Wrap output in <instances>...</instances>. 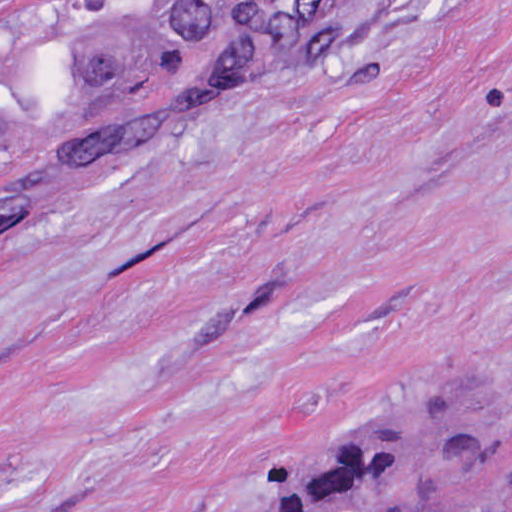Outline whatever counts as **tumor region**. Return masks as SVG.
I'll return each instance as SVG.
<instances>
[{
  "instance_id": "tumor-region-1",
  "label": "tumor region",
  "mask_w": 512,
  "mask_h": 512,
  "mask_svg": "<svg viewBox=\"0 0 512 512\" xmlns=\"http://www.w3.org/2000/svg\"><path fill=\"white\" fill-rule=\"evenodd\" d=\"M298 5L0 1V172L23 169L0 184V228L229 71ZM499 447L495 386L442 383L340 437L313 422L205 504L247 480L249 512H441Z\"/></svg>"
}]
</instances>
